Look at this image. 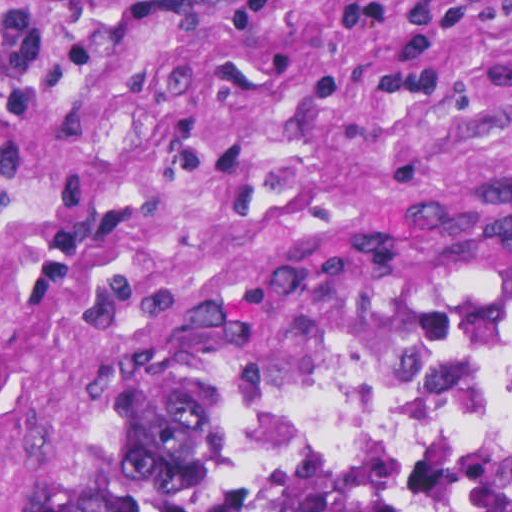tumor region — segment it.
<instances>
[{"mask_svg":"<svg viewBox=\"0 0 512 512\" xmlns=\"http://www.w3.org/2000/svg\"><path fill=\"white\" fill-rule=\"evenodd\" d=\"M511 306L512 243L375 240L292 268L204 354L183 391L49 512H101L120 494L175 486L512 512V460L439 446L307 444L278 428L281 402L322 352L378 325Z\"/></svg>","mask_w":512,"mask_h":512,"instance_id":"tumor-region-1","label":"tumor region"}]
</instances>
